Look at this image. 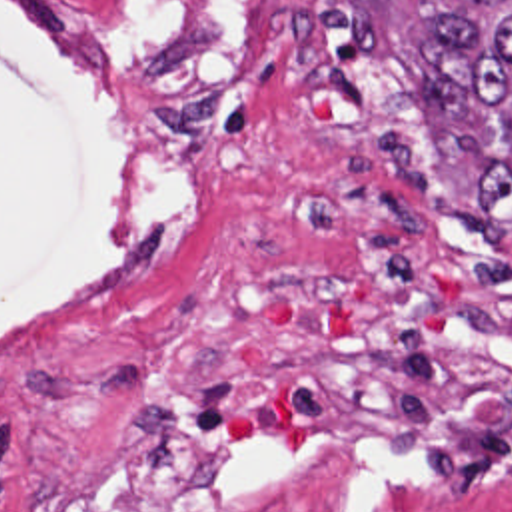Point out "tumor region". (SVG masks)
<instances>
[{
	"label": "tumor region",
	"instance_id": "e687c5a6",
	"mask_svg": "<svg viewBox=\"0 0 512 512\" xmlns=\"http://www.w3.org/2000/svg\"><path fill=\"white\" fill-rule=\"evenodd\" d=\"M430 22L412 44L422 92L458 156L478 168L464 228L512 234V0H408Z\"/></svg>",
	"mask_w": 512,
	"mask_h": 512
}]
</instances>
